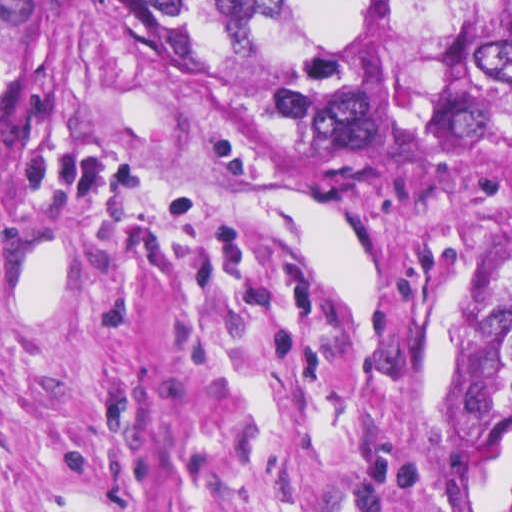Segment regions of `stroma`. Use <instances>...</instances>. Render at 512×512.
<instances>
[{"instance_id":"35a3bbf8","label":"stroma","mask_w":512,"mask_h":512,"mask_svg":"<svg viewBox=\"0 0 512 512\" xmlns=\"http://www.w3.org/2000/svg\"><path fill=\"white\" fill-rule=\"evenodd\" d=\"M511 240L512 157L379 161L0 0V512H512L464 403Z\"/></svg>"}]
</instances>
